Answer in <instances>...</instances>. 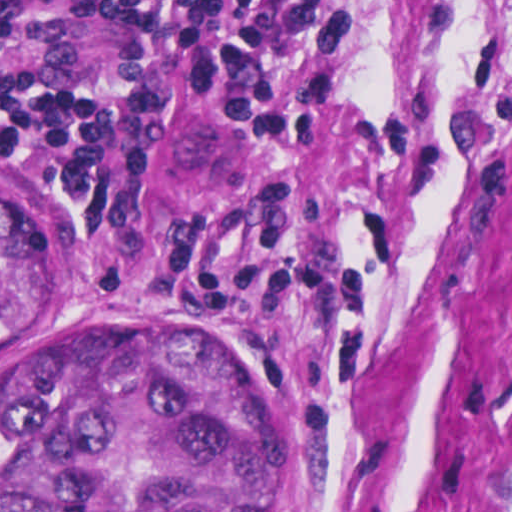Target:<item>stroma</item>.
Returning a JSON list of instances; mask_svg holds the SVG:
<instances>
[{"label": "stroma", "mask_w": 512, "mask_h": 512, "mask_svg": "<svg viewBox=\"0 0 512 512\" xmlns=\"http://www.w3.org/2000/svg\"><path fill=\"white\" fill-rule=\"evenodd\" d=\"M321 107L298 144L213 83L144 128L156 219H294L329 288L285 332L105 263L15 148L52 226L40 339L165 322L295 420L293 512H512V0H289ZM189 110L172 120L178 111Z\"/></svg>", "instance_id": "35a3bbf8"}]
</instances>
